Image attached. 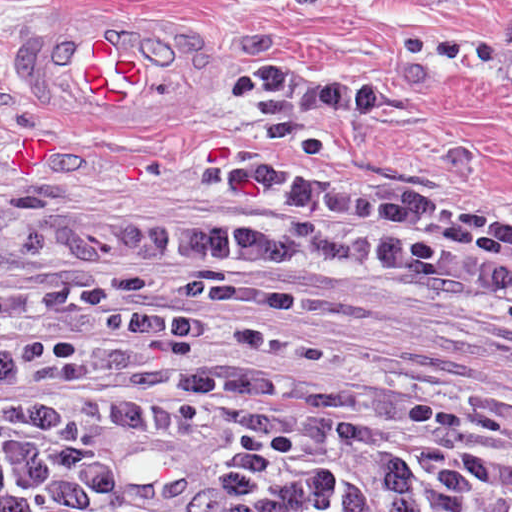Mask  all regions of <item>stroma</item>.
I'll list each match as a JSON object with an SVG mask.
<instances>
[{
  "label": "stroma",
  "mask_w": 512,
  "mask_h": 512,
  "mask_svg": "<svg viewBox=\"0 0 512 512\" xmlns=\"http://www.w3.org/2000/svg\"><path fill=\"white\" fill-rule=\"evenodd\" d=\"M252 65L390 85L398 107L230 95ZM225 171L512 234V0H0V222L191 236ZM289 276L369 307L283 311L329 349L322 397L461 417L512 459V291Z\"/></svg>",
  "instance_id": "1"
}]
</instances>
